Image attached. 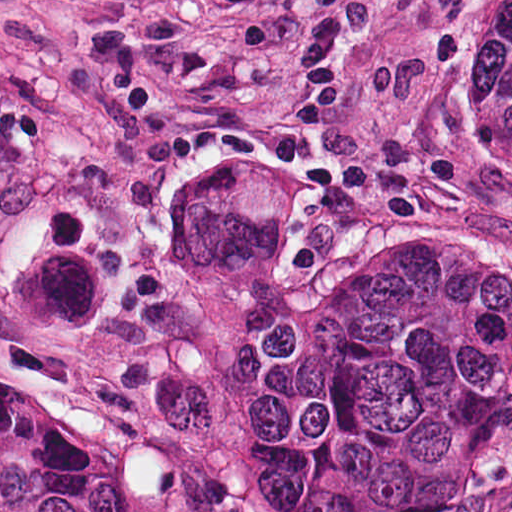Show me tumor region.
Segmentation results:
<instances>
[{
	"label": "tumor region",
	"instance_id": "e687c5a6",
	"mask_svg": "<svg viewBox=\"0 0 512 512\" xmlns=\"http://www.w3.org/2000/svg\"><path fill=\"white\" fill-rule=\"evenodd\" d=\"M511 362L489 258L428 250L371 272L331 265L264 377L249 490L408 497Z\"/></svg>",
	"mask_w": 512,
	"mask_h": 512
}]
</instances>
